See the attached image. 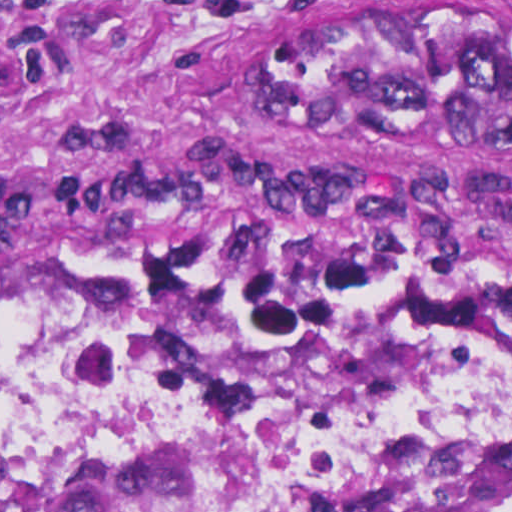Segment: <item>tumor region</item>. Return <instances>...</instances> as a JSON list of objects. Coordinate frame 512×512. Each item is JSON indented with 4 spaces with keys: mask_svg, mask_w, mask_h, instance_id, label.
Returning a JSON list of instances; mask_svg holds the SVG:
<instances>
[{
    "mask_svg": "<svg viewBox=\"0 0 512 512\" xmlns=\"http://www.w3.org/2000/svg\"><path fill=\"white\" fill-rule=\"evenodd\" d=\"M285 125L426 163H512V14L490 0L319 7L268 63ZM104 292L144 296L259 382L375 386L402 367L512 370V322L413 311L356 292L208 261H144L0 243V306ZM0 512H265L226 461L29 465L0 460ZM340 512H512V476L420 454L358 486Z\"/></svg>",
    "mask_w": 512,
    "mask_h": 512,
    "instance_id": "e687c5a6",
    "label": "tumor region"
}]
</instances>
